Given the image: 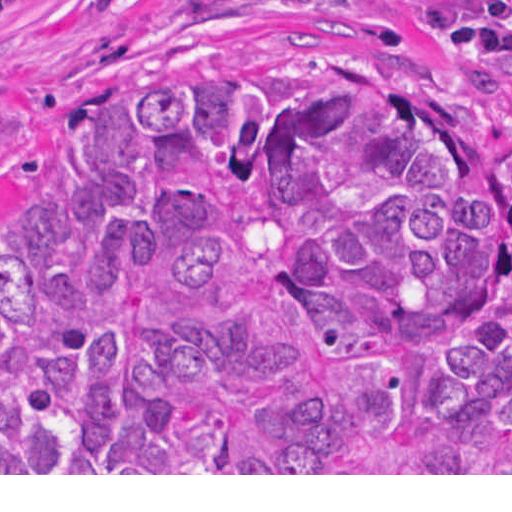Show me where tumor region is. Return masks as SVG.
<instances>
[{
    "mask_svg": "<svg viewBox=\"0 0 512 512\" xmlns=\"http://www.w3.org/2000/svg\"><path fill=\"white\" fill-rule=\"evenodd\" d=\"M415 14L512 93V0ZM0 473H512V127L310 57L103 96L0 263Z\"/></svg>",
    "mask_w": 512,
    "mask_h": 512,
    "instance_id": "e687c5a6",
    "label": "tumor region"
}]
</instances>
